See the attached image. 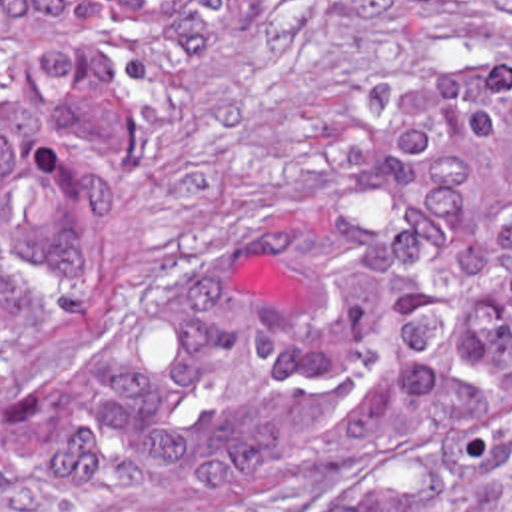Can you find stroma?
<instances>
[{"mask_svg":"<svg viewBox=\"0 0 512 512\" xmlns=\"http://www.w3.org/2000/svg\"><path fill=\"white\" fill-rule=\"evenodd\" d=\"M439 59L512 63V11L411 15L383 0H243L160 113L116 219V271L82 335L0 368V512H512V440L453 442L359 478L156 488L62 510L14 444L106 331L140 311L247 203Z\"/></svg>","mask_w":512,"mask_h":512,"instance_id":"1","label":"stroma"}]
</instances>
